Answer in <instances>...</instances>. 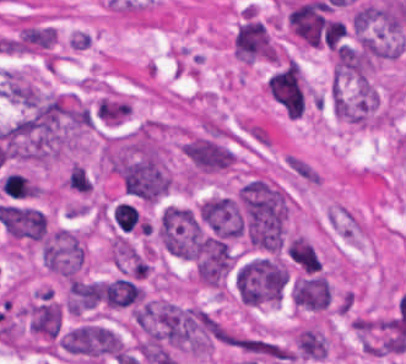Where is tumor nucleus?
<instances>
[{
  "mask_svg": "<svg viewBox=\"0 0 406 364\" xmlns=\"http://www.w3.org/2000/svg\"><path fill=\"white\" fill-rule=\"evenodd\" d=\"M101 293L105 306L115 310L137 305L145 299L142 287L124 278L105 280L101 284Z\"/></svg>",
  "mask_w": 406,
  "mask_h": 364,
  "instance_id": "tumor-nucleus-7",
  "label": "tumor nucleus"
},
{
  "mask_svg": "<svg viewBox=\"0 0 406 364\" xmlns=\"http://www.w3.org/2000/svg\"><path fill=\"white\" fill-rule=\"evenodd\" d=\"M85 263V245L81 236L56 229L44 244V265L63 280L78 276Z\"/></svg>",
  "mask_w": 406,
  "mask_h": 364,
  "instance_id": "tumor-nucleus-4",
  "label": "tumor nucleus"
},
{
  "mask_svg": "<svg viewBox=\"0 0 406 364\" xmlns=\"http://www.w3.org/2000/svg\"><path fill=\"white\" fill-rule=\"evenodd\" d=\"M289 295L303 311L322 312V271L295 275Z\"/></svg>",
  "mask_w": 406,
  "mask_h": 364,
  "instance_id": "tumor-nucleus-6",
  "label": "tumor nucleus"
},
{
  "mask_svg": "<svg viewBox=\"0 0 406 364\" xmlns=\"http://www.w3.org/2000/svg\"><path fill=\"white\" fill-rule=\"evenodd\" d=\"M289 279V270L278 258H252L239 269L236 279L241 300L247 304L278 302Z\"/></svg>",
  "mask_w": 406,
  "mask_h": 364,
  "instance_id": "tumor-nucleus-3",
  "label": "tumor nucleus"
},
{
  "mask_svg": "<svg viewBox=\"0 0 406 364\" xmlns=\"http://www.w3.org/2000/svg\"><path fill=\"white\" fill-rule=\"evenodd\" d=\"M59 346L75 360L102 364L117 358L126 349V342L111 328L85 321L60 333Z\"/></svg>",
  "mask_w": 406,
  "mask_h": 364,
  "instance_id": "tumor-nucleus-2",
  "label": "tumor nucleus"
},
{
  "mask_svg": "<svg viewBox=\"0 0 406 364\" xmlns=\"http://www.w3.org/2000/svg\"><path fill=\"white\" fill-rule=\"evenodd\" d=\"M199 218L218 237H240L243 216L235 199L214 196L198 206Z\"/></svg>",
  "mask_w": 406,
  "mask_h": 364,
  "instance_id": "tumor-nucleus-5",
  "label": "tumor nucleus"
},
{
  "mask_svg": "<svg viewBox=\"0 0 406 364\" xmlns=\"http://www.w3.org/2000/svg\"><path fill=\"white\" fill-rule=\"evenodd\" d=\"M239 206L246 245L278 253L284 246L290 211L284 191L257 177L241 188Z\"/></svg>",
  "mask_w": 406,
  "mask_h": 364,
  "instance_id": "tumor-nucleus-1",
  "label": "tumor nucleus"
},
{
  "mask_svg": "<svg viewBox=\"0 0 406 364\" xmlns=\"http://www.w3.org/2000/svg\"><path fill=\"white\" fill-rule=\"evenodd\" d=\"M100 297V282L75 278L68 284L66 310L79 316L97 303Z\"/></svg>",
  "mask_w": 406,
  "mask_h": 364,
  "instance_id": "tumor-nucleus-8",
  "label": "tumor nucleus"
}]
</instances>
